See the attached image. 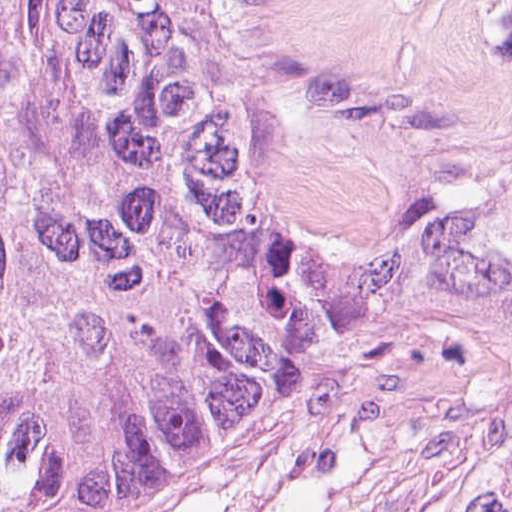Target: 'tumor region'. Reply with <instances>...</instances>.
<instances>
[{"label": "tumor region", "instance_id": "tumor-region-1", "mask_svg": "<svg viewBox=\"0 0 512 512\" xmlns=\"http://www.w3.org/2000/svg\"><path fill=\"white\" fill-rule=\"evenodd\" d=\"M283 0H0V512L195 499L306 401L322 300L499 407L444 512H512V174L313 279L276 218Z\"/></svg>", "mask_w": 512, "mask_h": 512}]
</instances>
